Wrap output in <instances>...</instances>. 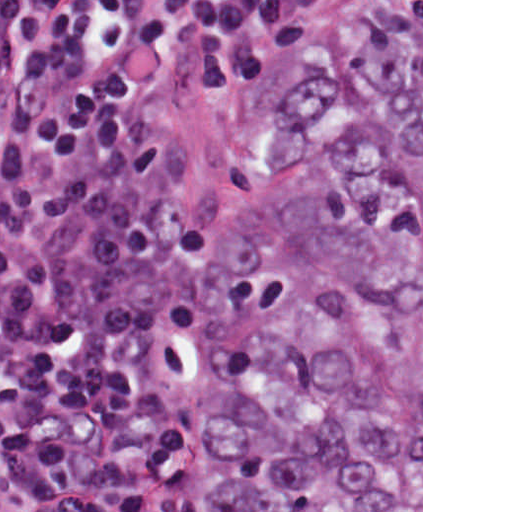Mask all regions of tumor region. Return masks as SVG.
Instances as JSON below:
<instances>
[{"instance_id": "tumor-region-1", "label": "tumor region", "mask_w": 512, "mask_h": 512, "mask_svg": "<svg viewBox=\"0 0 512 512\" xmlns=\"http://www.w3.org/2000/svg\"><path fill=\"white\" fill-rule=\"evenodd\" d=\"M167 512H421V3L294 50L226 201Z\"/></svg>"}]
</instances>
